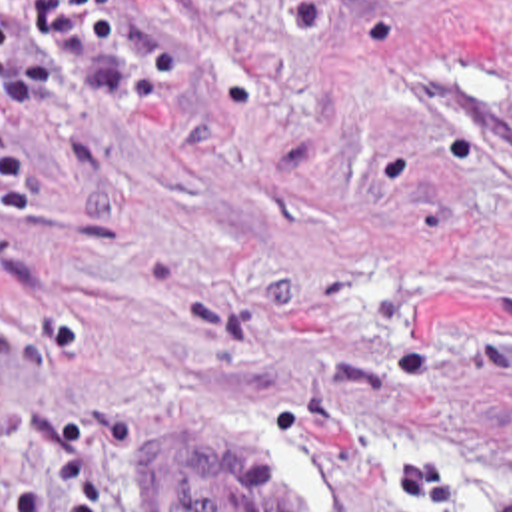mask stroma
<instances>
[{
    "mask_svg": "<svg viewBox=\"0 0 512 512\" xmlns=\"http://www.w3.org/2000/svg\"><path fill=\"white\" fill-rule=\"evenodd\" d=\"M0 104V512H512V0H127Z\"/></svg>",
    "mask_w": 512,
    "mask_h": 512,
    "instance_id": "stroma-1",
    "label": "stroma"
}]
</instances>
